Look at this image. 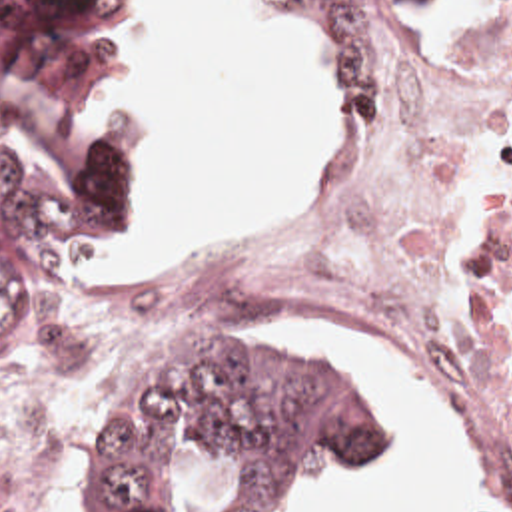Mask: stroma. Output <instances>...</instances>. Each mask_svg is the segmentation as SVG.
<instances>
[{"label":"stroma","mask_w":512,"mask_h":512,"mask_svg":"<svg viewBox=\"0 0 512 512\" xmlns=\"http://www.w3.org/2000/svg\"><path fill=\"white\" fill-rule=\"evenodd\" d=\"M469 1L473 0L445 1L433 13H429L421 21H417L413 39H411V47H409V59H407L405 81H403L401 91L395 95L391 105L373 119V123L367 129H339L335 149L329 155V159L325 161L319 175L341 171L369 151V147L375 141V137L379 135L381 127L385 125V121L389 119V115L393 113V109L397 107V103L403 99V95L407 93V89L413 83L417 55H419L421 45L427 41V37L433 33V29L439 25V21L445 15L453 13L455 9L463 7ZM130 141H132V135H130ZM138 181H140V191H142V199H144V187H142L140 175H138ZM301 193L289 197L283 217L269 231L241 239L232 245L196 253L190 259H186L182 265H178L174 271L166 273L164 277H144L136 283L118 285V287H110V289H80V287H76L74 277H72L74 263L80 259H74L68 265H64L60 271H56L52 277L46 279V313H44V321L40 328L36 354H34V360H32L26 376L30 374V370L36 366L38 360L72 354L78 386L74 388V392L68 396V400L62 404V408L54 416V466H56L58 488H60V496L64 500L66 512H76L74 510V470H76V462H78V454H80L86 420L98 408V404L106 398V394L112 390V386L118 382V378L142 362V360H134V362H76L64 323L70 317V313L76 309L80 299L88 297V295L110 293V291L164 289V287H174V285H182L190 279H196V277L228 263L230 259L238 257L241 253L275 239L277 231L281 229L283 221L287 219L289 211L293 209V205ZM220 326H317L327 336H331L337 344H341L347 352H351L355 358H359L363 364H367L371 368V372L377 380V386L381 390V396L387 404L395 370L381 358V356H385L389 362H393L397 366V374L403 378V382L411 390H415L421 398H425L429 404H433L437 410H441L445 416H449L453 420L455 432L459 438V446L471 466V494L461 510V512H469L473 486H475V438H473L471 416H469V410H467L461 394L457 392L453 380L441 368H437L425 354L389 338L387 334L363 323L357 317H281V319H273V321H265V323H257V325ZM22 388H26V386L2 388L0 398L12 394L16 390H22ZM385 452H387V438H385L383 446L379 448V452L375 454L373 462L367 466L377 468L381 472Z\"/></svg>","instance_id":"1"}]
</instances>
